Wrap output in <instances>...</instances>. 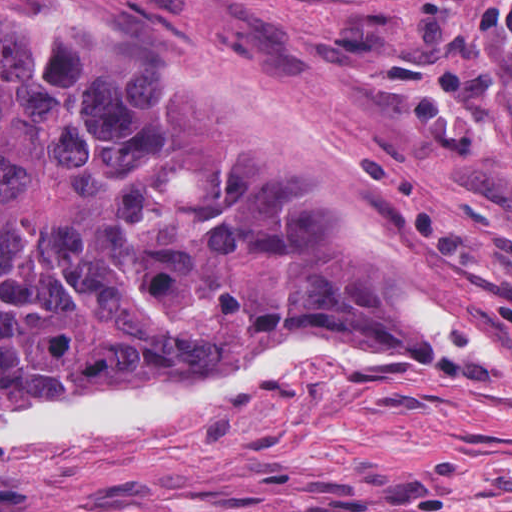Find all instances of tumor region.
<instances>
[{
  "instance_id": "1",
  "label": "tumor region",
  "mask_w": 512,
  "mask_h": 512,
  "mask_svg": "<svg viewBox=\"0 0 512 512\" xmlns=\"http://www.w3.org/2000/svg\"><path fill=\"white\" fill-rule=\"evenodd\" d=\"M351 310L472 336L414 307L313 150L229 98L0 43V416L207 381Z\"/></svg>"
}]
</instances>
